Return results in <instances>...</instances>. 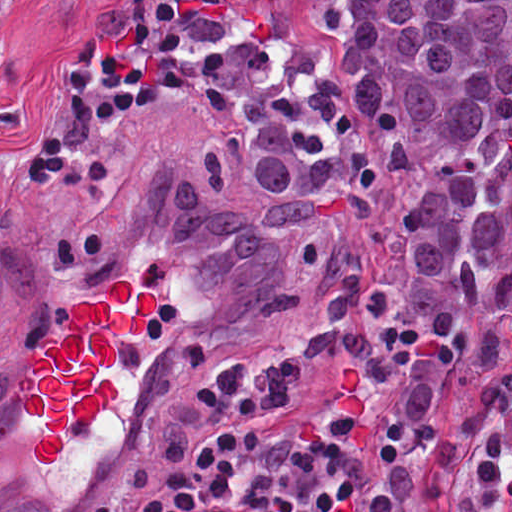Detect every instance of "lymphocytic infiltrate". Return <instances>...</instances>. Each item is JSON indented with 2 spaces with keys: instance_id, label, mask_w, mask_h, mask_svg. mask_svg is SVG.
<instances>
[{
  "instance_id": "1",
  "label": "lymphocytic infiltrate",
  "mask_w": 512,
  "mask_h": 512,
  "mask_svg": "<svg viewBox=\"0 0 512 512\" xmlns=\"http://www.w3.org/2000/svg\"><path fill=\"white\" fill-rule=\"evenodd\" d=\"M21 0H0V86L13 79ZM191 83V25L172 0H130V30L74 45L70 85L39 112L23 167L79 189L106 171L97 126L150 117ZM284 371L218 362L164 389L147 454L114 475L91 512H361V462L286 420ZM298 381V380H297ZM299 382V381H298Z\"/></svg>"
}]
</instances>
